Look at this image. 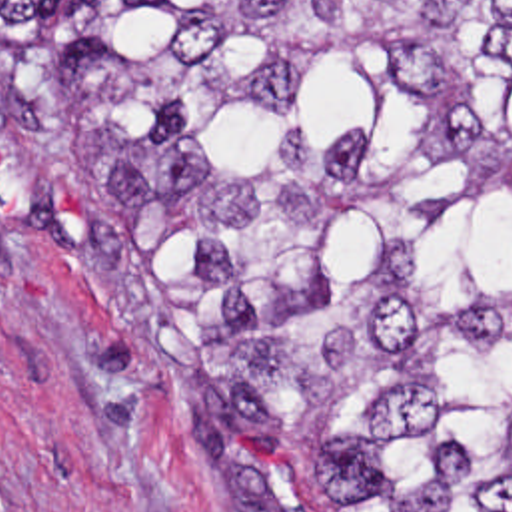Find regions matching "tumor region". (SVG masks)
<instances>
[{
    "label": "tumor region",
    "instance_id": "obj_1",
    "mask_svg": "<svg viewBox=\"0 0 512 512\" xmlns=\"http://www.w3.org/2000/svg\"><path fill=\"white\" fill-rule=\"evenodd\" d=\"M15 3L221 510L512 512V0Z\"/></svg>",
    "mask_w": 512,
    "mask_h": 512
}]
</instances>
